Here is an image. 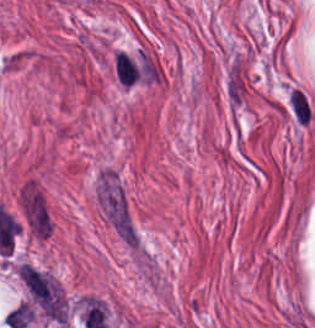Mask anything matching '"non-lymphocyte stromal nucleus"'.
I'll list each match as a JSON object with an SVG mask.
<instances>
[{"mask_svg": "<svg viewBox=\"0 0 315 328\" xmlns=\"http://www.w3.org/2000/svg\"><path fill=\"white\" fill-rule=\"evenodd\" d=\"M287 106L298 125H309L313 121V103L298 85H291L288 89Z\"/></svg>", "mask_w": 315, "mask_h": 328, "instance_id": "3", "label": "non-lymphocyte stromal nucleus"}, {"mask_svg": "<svg viewBox=\"0 0 315 328\" xmlns=\"http://www.w3.org/2000/svg\"><path fill=\"white\" fill-rule=\"evenodd\" d=\"M18 210L24 233L34 241L47 243L56 221L47 194L34 177L20 185Z\"/></svg>", "mask_w": 315, "mask_h": 328, "instance_id": "2", "label": "non-lymphocyte stromal nucleus"}, {"mask_svg": "<svg viewBox=\"0 0 315 328\" xmlns=\"http://www.w3.org/2000/svg\"><path fill=\"white\" fill-rule=\"evenodd\" d=\"M115 69L119 83L132 85L140 76L129 55L118 52L115 55Z\"/></svg>", "mask_w": 315, "mask_h": 328, "instance_id": "4", "label": "non-lymphocyte stromal nucleus"}, {"mask_svg": "<svg viewBox=\"0 0 315 328\" xmlns=\"http://www.w3.org/2000/svg\"><path fill=\"white\" fill-rule=\"evenodd\" d=\"M94 205L113 236L131 252L142 253L130 193L116 167L107 164L95 176Z\"/></svg>", "mask_w": 315, "mask_h": 328, "instance_id": "1", "label": "non-lymphocyte stromal nucleus"}]
</instances>
